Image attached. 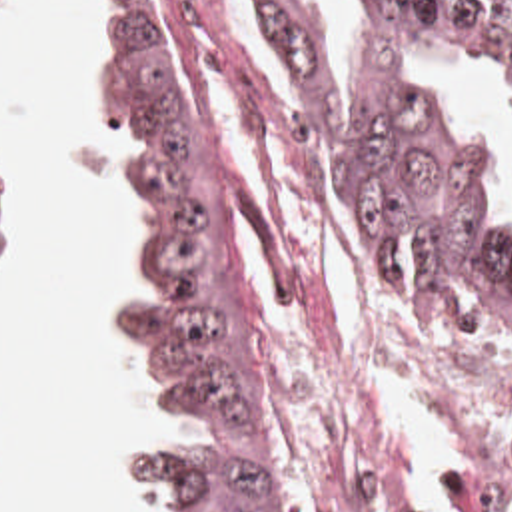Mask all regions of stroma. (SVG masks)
Listing matches in <instances>:
<instances>
[{
    "label": "stroma",
    "mask_w": 512,
    "mask_h": 512,
    "mask_svg": "<svg viewBox=\"0 0 512 512\" xmlns=\"http://www.w3.org/2000/svg\"><path fill=\"white\" fill-rule=\"evenodd\" d=\"M152 1L186 79L194 131L208 159L222 243L262 353L270 419L284 478V512H288L286 482L294 476L304 480L326 504L370 508L378 498L398 490L404 476V454L376 419L362 355L348 341L308 339L280 325L248 285L230 249V209H242L260 229L272 253L304 283L308 293L322 295L330 289L332 271L326 251L292 245L274 231L260 205L234 175L210 125L204 75L214 69L258 153L270 159L288 153L272 111L258 105L254 63L220 1ZM4 3L6 0L2 7ZM98 5L102 37V0ZM104 135L112 147L114 169L132 191L130 165L138 151L136 139L126 131L104 129ZM138 223L136 203V239ZM354 243L362 263L368 327L374 343L440 413L464 464V512H476L466 486V460L512 426V333L472 319H446L430 311L382 271L356 239ZM14 245L16 215L12 199L0 183V271L10 261ZM128 277L130 271L122 283ZM108 303L110 297L104 301V329L132 347L114 329ZM158 432L162 428L152 413V381L146 373V417L136 442ZM108 482L178 512V498L160 488H144L122 470L120 460L114 462Z\"/></svg>",
    "instance_id": "1"
}]
</instances>
